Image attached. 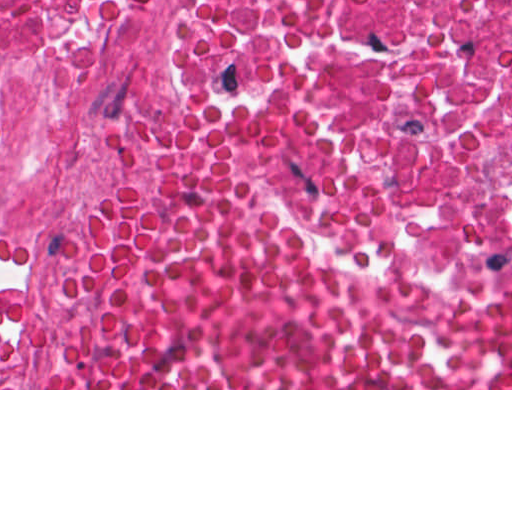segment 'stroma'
<instances>
[{
    "label": "stroma",
    "instance_id": "35a3bbf8",
    "mask_svg": "<svg viewBox=\"0 0 512 512\" xmlns=\"http://www.w3.org/2000/svg\"><path fill=\"white\" fill-rule=\"evenodd\" d=\"M203 113L239 126L307 242L357 303L374 311H475L512 306V280L431 278L407 260L353 146L328 114L231 78L228 43L148 63L106 105L66 210V246L113 195L126 160L151 128ZM0 390H512V388H62L56 329L34 362Z\"/></svg>",
    "mask_w": 512,
    "mask_h": 512
}]
</instances>
